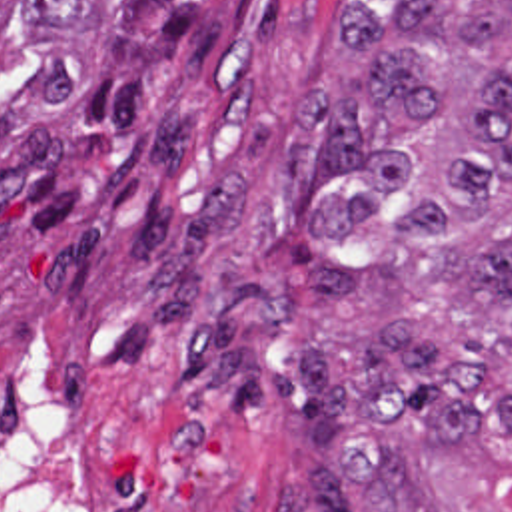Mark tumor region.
<instances>
[{
	"instance_id": "obj_1",
	"label": "tumor region",
	"mask_w": 512,
	"mask_h": 512,
	"mask_svg": "<svg viewBox=\"0 0 512 512\" xmlns=\"http://www.w3.org/2000/svg\"><path fill=\"white\" fill-rule=\"evenodd\" d=\"M356 95L296 97L280 185L316 187V302L374 318L268 362L288 293L228 285L182 358L232 408L286 402L322 462L276 512H512V0L350 1Z\"/></svg>"
}]
</instances>
